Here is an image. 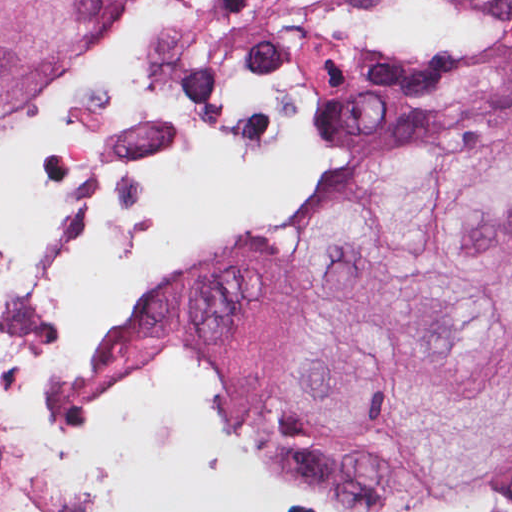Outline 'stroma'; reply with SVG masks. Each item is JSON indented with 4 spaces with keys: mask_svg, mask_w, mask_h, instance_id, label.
Listing matches in <instances>:
<instances>
[{
    "mask_svg": "<svg viewBox=\"0 0 512 512\" xmlns=\"http://www.w3.org/2000/svg\"><path fill=\"white\" fill-rule=\"evenodd\" d=\"M368 1L378 13L380 0ZM466 1V24L438 42L398 43L380 30L376 43L346 64H385L420 70L432 80L447 109L512 112L510 103L469 92L465 73L488 40L512 35V0ZM290 98L306 104L308 109L309 161L278 188L267 204L201 253L216 246L259 241L274 232L296 207L318 157L321 120L309 84ZM24 111L0 121V133L20 122ZM270 123L271 120L247 146L232 152L261 154ZM185 260L161 265L129 280L96 304L88 327L86 363L70 394L55 408L39 415L15 416L4 405L8 357L0 358V512H90L62 468V448L70 433L92 427L113 413L157 398L172 388L188 400L204 426L250 478L258 496L244 512H512V447L420 496L385 507H349L300 490L257 462L251 456L250 418L231 398L200 378L180 346L160 352L143 369L107 373L110 321L149 288L140 314L163 280ZM79 274L65 292L55 317L64 312Z\"/></svg>",
    "mask_w": 512,
    "mask_h": 512,
    "instance_id": "stroma-1",
    "label": "stroma"
}]
</instances>
